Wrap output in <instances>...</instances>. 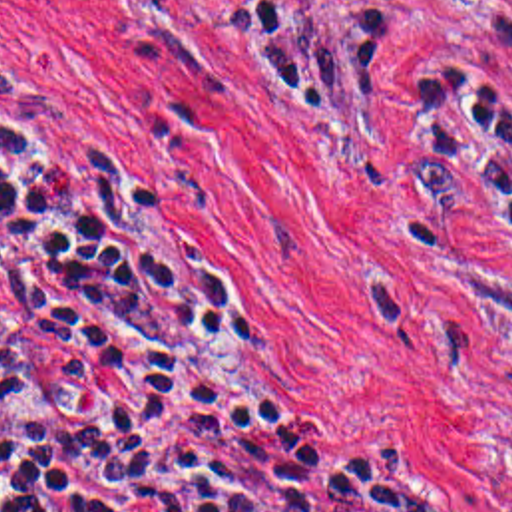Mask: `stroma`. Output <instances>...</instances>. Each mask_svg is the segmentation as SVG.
<instances>
[{
    "mask_svg": "<svg viewBox=\"0 0 512 512\" xmlns=\"http://www.w3.org/2000/svg\"><path fill=\"white\" fill-rule=\"evenodd\" d=\"M385 41L367 99H269L233 0H0V61L148 252L351 455L512 512V246L417 166L431 67L512 109V0H237Z\"/></svg>",
    "mask_w": 512,
    "mask_h": 512,
    "instance_id": "stroma-1",
    "label": "stroma"
}]
</instances>
